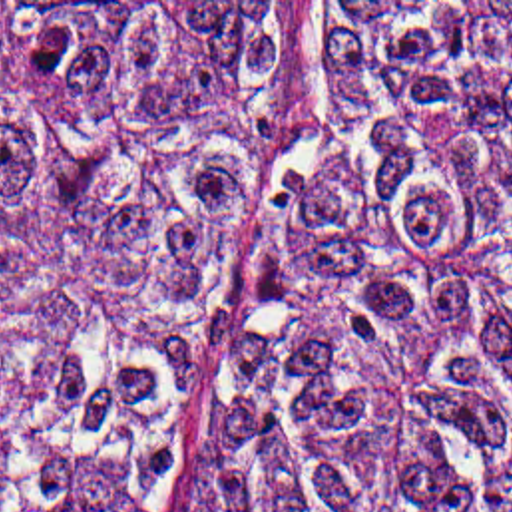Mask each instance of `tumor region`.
<instances>
[{
	"label": "tumor region",
	"instance_id": "e687c5a6",
	"mask_svg": "<svg viewBox=\"0 0 512 512\" xmlns=\"http://www.w3.org/2000/svg\"><path fill=\"white\" fill-rule=\"evenodd\" d=\"M286 54L288 2H0V512H148ZM170 512H512V2H330Z\"/></svg>",
	"mask_w": 512,
	"mask_h": 512
}]
</instances>
